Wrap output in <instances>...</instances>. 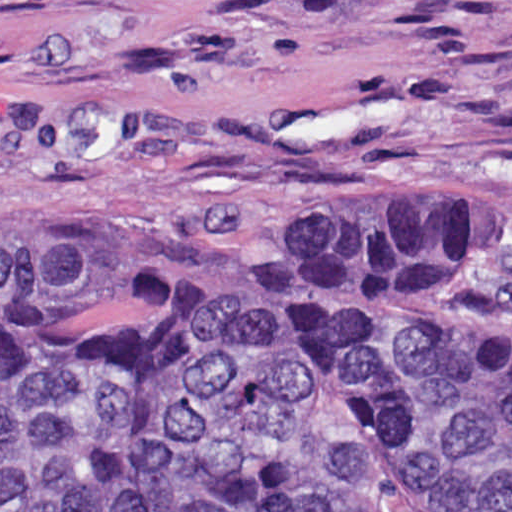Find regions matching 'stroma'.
Segmentation results:
<instances>
[{
    "mask_svg": "<svg viewBox=\"0 0 512 512\" xmlns=\"http://www.w3.org/2000/svg\"><path fill=\"white\" fill-rule=\"evenodd\" d=\"M0 208L118 264L272 212H504L458 292L512 332V0H0Z\"/></svg>",
    "mask_w": 512,
    "mask_h": 512,
    "instance_id": "obj_1",
    "label": "stroma"
}]
</instances>
